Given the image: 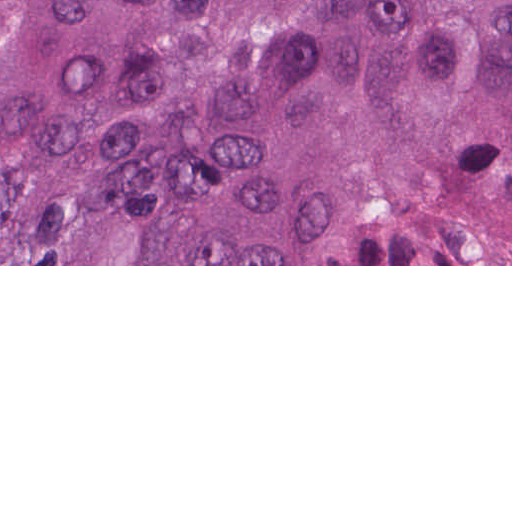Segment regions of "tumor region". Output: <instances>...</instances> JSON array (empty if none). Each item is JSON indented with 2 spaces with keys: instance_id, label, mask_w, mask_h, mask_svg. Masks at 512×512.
Here are the masks:
<instances>
[{
  "instance_id": "e687c5a6",
  "label": "tumor region",
  "mask_w": 512,
  "mask_h": 512,
  "mask_svg": "<svg viewBox=\"0 0 512 512\" xmlns=\"http://www.w3.org/2000/svg\"><path fill=\"white\" fill-rule=\"evenodd\" d=\"M0 264H512V0H0Z\"/></svg>"
}]
</instances>
